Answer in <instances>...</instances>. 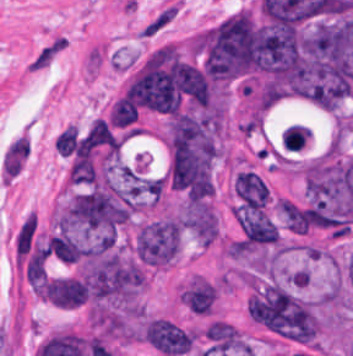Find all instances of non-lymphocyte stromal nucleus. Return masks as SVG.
Returning a JSON list of instances; mask_svg holds the SVG:
<instances>
[{"label":"non-lymphocyte stromal nucleus","instance_id":"1","mask_svg":"<svg viewBox=\"0 0 353 356\" xmlns=\"http://www.w3.org/2000/svg\"><path fill=\"white\" fill-rule=\"evenodd\" d=\"M30 143L26 135H19L8 146L2 168L4 178L13 179L24 167Z\"/></svg>","mask_w":353,"mask_h":356},{"label":"non-lymphocyte stromal nucleus","instance_id":"2","mask_svg":"<svg viewBox=\"0 0 353 356\" xmlns=\"http://www.w3.org/2000/svg\"><path fill=\"white\" fill-rule=\"evenodd\" d=\"M66 48V38L62 34H55L35 51L26 69L28 71L46 69Z\"/></svg>","mask_w":353,"mask_h":356},{"label":"non-lymphocyte stromal nucleus","instance_id":"3","mask_svg":"<svg viewBox=\"0 0 353 356\" xmlns=\"http://www.w3.org/2000/svg\"><path fill=\"white\" fill-rule=\"evenodd\" d=\"M178 11V2L175 0H168L141 26L139 30L140 34L142 37H155L173 21Z\"/></svg>","mask_w":353,"mask_h":356},{"label":"non-lymphocyte stromal nucleus","instance_id":"4","mask_svg":"<svg viewBox=\"0 0 353 356\" xmlns=\"http://www.w3.org/2000/svg\"><path fill=\"white\" fill-rule=\"evenodd\" d=\"M37 227L36 214L32 211L25 217L20 225L14 240L15 256L24 259L29 252Z\"/></svg>","mask_w":353,"mask_h":356}]
</instances>
